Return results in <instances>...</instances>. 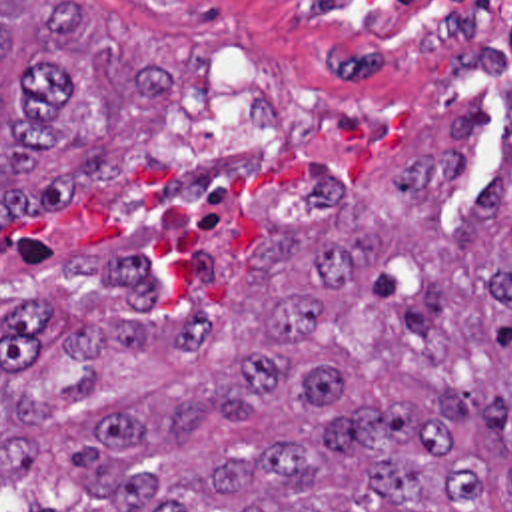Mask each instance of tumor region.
I'll use <instances>...</instances> for the list:
<instances>
[{
  "instance_id": "tumor-region-1",
  "label": "tumor region",
  "mask_w": 512,
  "mask_h": 512,
  "mask_svg": "<svg viewBox=\"0 0 512 512\" xmlns=\"http://www.w3.org/2000/svg\"><path fill=\"white\" fill-rule=\"evenodd\" d=\"M469 217L447 221L491 107L252 257L74 255L94 285L0 309V480L28 512H512V79ZM176 99V47L86 0H0V225L114 177L126 109Z\"/></svg>"
}]
</instances>
